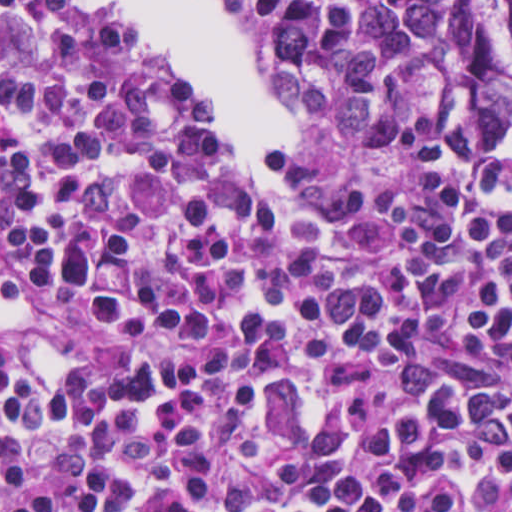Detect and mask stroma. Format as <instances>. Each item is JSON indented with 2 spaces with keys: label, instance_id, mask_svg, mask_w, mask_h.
Returning a JSON list of instances; mask_svg holds the SVG:
<instances>
[{
  "label": "stroma",
  "instance_id": "1",
  "mask_svg": "<svg viewBox=\"0 0 512 512\" xmlns=\"http://www.w3.org/2000/svg\"><path fill=\"white\" fill-rule=\"evenodd\" d=\"M219 3H220V6L222 8V10L230 17H232L233 19H235L225 8V5H224V2L223 0H218ZM236 20V19H235ZM238 21V20H236ZM239 23H241L240 21H238ZM242 25H244L243 23H241ZM246 27V29L248 30V32L251 34L255 44L257 45L259 51H260V48H259V44H258V40H257V36L256 34L253 32V30L251 28H249L248 26L244 25ZM173 69V68H172ZM267 76V74H266ZM267 79H268V83L271 87V89L273 90V92L275 93L280 105H283L281 103V101L279 100L277 94H276V91L269 79V77L267 76ZM512 121V117L509 119V121L506 123L505 127ZM504 127V128H505ZM320 129V128H319ZM321 130V129H320ZM323 131V130H322ZM325 132V131H324ZM327 133V132H326ZM330 134V133H328ZM332 135V134H330ZM334 136V135H332ZM335 137V136H334ZM337 138V137H335ZM338 139V138H337ZM411 139H425V140H432V141H436L434 140L433 138H428V137H414V138H411ZM450 145H481V144H450ZM503 159H510L512 160V149L508 151V153L505 155V157ZM309 167V166H308ZM309 169L312 171V173L314 174L315 178L321 183V184H329L325 181V179L322 177V175L317 172L314 168L312 167H309ZM454 174H455V177L457 179V181L459 182L460 186L471 176L469 174H465V173H461V172H458L456 170H454ZM412 182V181H411ZM410 183V182H409ZM404 187L400 188L399 190L393 192V193H377V194H385L386 196L390 197V198H395V197H399L402 190H403ZM253 194H256V193H253Z\"/></svg>",
  "mask_w": 512,
  "mask_h": 512
}]
</instances>
